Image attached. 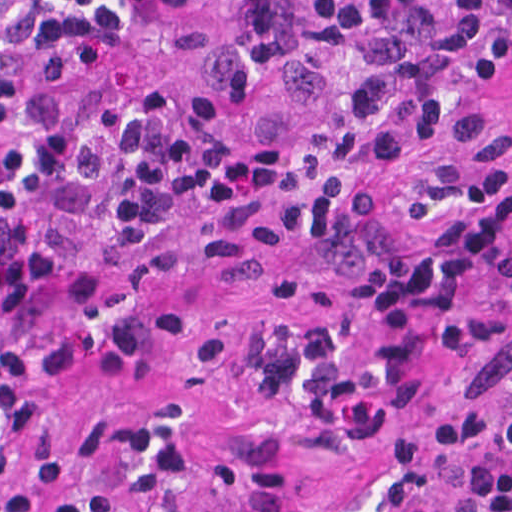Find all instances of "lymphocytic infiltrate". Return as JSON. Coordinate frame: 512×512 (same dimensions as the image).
I'll return each mask as SVG.
<instances>
[{
  "instance_id": "f902f5d3",
  "label": "lymphocytic infiltrate",
  "mask_w": 512,
  "mask_h": 512,
  "mask_svg": "<svg viewBox=\"0 0 512 512\" xmlns=\"http://www.w3.org/2000/svg\"><path fill=\"white\" fill-rule=\"evenodd\" d=\"M504 1L295 0L298 30L351 79L301 187L307 264L341 280L336 298L253 347L217 464L211 437L117 409L90 434L77 492L50 379L99 329L52 312L49 222L73 215L125 284L179 217L256 219L285 150L241 146L208 93L69 94L106 44L204 48L203 0H0V512H258L308 426L359 405L403 343L493 285L512 261V157L484 163L474 196L445 215L392 216L378 187L404 154L461 134L465 54ZM481 62L512 89V12L487 28ZM345 512H512V360L438 384Z\"/></svg>"
}]
</instances>
